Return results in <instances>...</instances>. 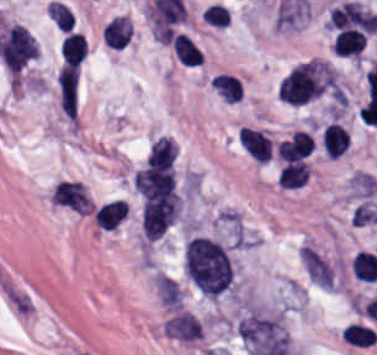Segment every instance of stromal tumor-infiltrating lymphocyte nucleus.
I'll return each instance as SVG.
<instances>
[{"label":"stromal tumor-infiltrating lymphocyte nucleus","mask_w":377,"mask_h":355,"mask_svg":"<svg viewBox=\"0 0 377 355\" xmlns=\"http://www.w3.org/2000/svg\"><path fill=\"white\" fill-rule=\"evenodd\" d=\"M125 213L124 201L116 199L99 206L94 212V221L104 230H113Z\"/></svg>","instance_id":"f3e2335f"},{"label":"stromal tumor-infiltrating lymphocyte nucleus","mask_w":377,"mask_h":355,"mask_svg":"<svg viewBox=\"0 0 377 355\" xmlns=\"http://www.w3.org/2000/svg\"><path fill=\"white\" fill-rule=\"evenodd\" d=\"M309 176L306 163L302 161L288 162L283 165L277 185L284 189H298Z\"/></svg>","instance_id":"4f13568d"},{"label":"stromal tumor-infiltrating lymphocyte nucleus","mask_w":377,"mask_h":355,"mask_svg":"<svg viewBox=\"0 0 377 355\" xmlns=\"http://www.w3.org/2000/svg\"><path fill=\"white\" fill-rule=\"evenodd\" d=\"M48 14L60 31H69L73 27L74 15L71 9L58 1L47 4Z\"/></svg>","instance_id":"4803ca6d"},{"label":"stromal tumor-infiltrating lymphocyte nucleus","mask_w":377,"mask_h":355,"mask_svg":"<svg viewBox=\"0 0 377 355\" xmlns=\"http://www.w3.org/2000/svg\"><path fill=\"white\" fill-rule=\"evenodd\" d=\"M132 27L126 16L115 15L113 16L103 28L102 40L115 49H122L130 35Z\"/></svg>","instance_id":"abfb95fc"},{"label":"stromal tumor-infiltrating lymphocyte nucleus","mask_w":377,"mask_h":355,"mask_svg":"<svg viewBox=\"0 0 377 355\" xmlns=\"http://www.w3.org/2000/svg\"><path fill=\"white\" fill-rule=\"evenodd\" d=\"M207 22L214 26H227L230 20V11L225 4L211 2L203 14Z\"/></svg>","instance_id":"4245b91a"},{"label":"stromal tumor-infiltrating lymphocyte nucleus","mask_w":377,"mask_h":355,"mask_svg":"<svg viewBox=\"0 0 377 355\" xmlns=\"http://www.w3.org/2000/svg\"><path fill=\"white\" fill-rule=\"evenodd\" d=\"M172 49L183 65H200L204 59L193 39L184 32H177L173 36Z\"/></svg>","instance_id":"9ea309e8"},{"label":"stromal tumor-infiltrating lymphocyte nucleus","mask_w":377,"mask_h":355,"mask_svg":"<svg viewBox=\"0 0 377 355\" xmlns=\"http://www.w3.org/2000/svg\"><path fill=\"white\" fill-rule=\"evenodd\" d=\"M321 143L330 158H337L346 152L349 136L341 123L329 122L321 132Z\"/></svg>","instance_id":"3290ff9b"},{"label":"stromal tumor-infiltrating lymphocyte nucleus","mask_w":377,"mask_h":355,"mask_svg":"<svg viewBox=\"0 0 377 355\" xmlns=\"http://www.w3.org/2000/svg\"><path fill=\"white\" fill-rule=\"evenodd\" d=\"M213 82L225 101L235 102L242 98V85L237 76L218 73Z\"/></svg>","instance_id":"2a367800"},{"label":"stromal tumor-infiltrating lymphocyte nucleus","mask_w":377,"mask_h":355,"mask_svg":"<svg viewBox=\"0 0 377 355\" xmlns=\"http://www.w3.org/2000/svg\"><path fill=\"white\" fill-rule=\"evenodd\" d=\"M336 82L325 60H305L287 74L279 89L281 99L290 105H304Z\"/></svg>","instance_id":"bc302bb0"},{"label":"stromal tumor-infiltrating lymphocyte nucleus","mask_w":377,"mask_h":355,"mask_svg":"<svg viewBox=\"0 0 377 355\" xmlns=\"http://www.w3.org/2000/svg\"><path fill=\"white\" fill-rule=\"evenodd\" d=\"M239 140L251 156L261 161H268L273 142L266 133L242 126Z\"/></svg>","instance_id":"52c7bb5b"}]
</instances>
